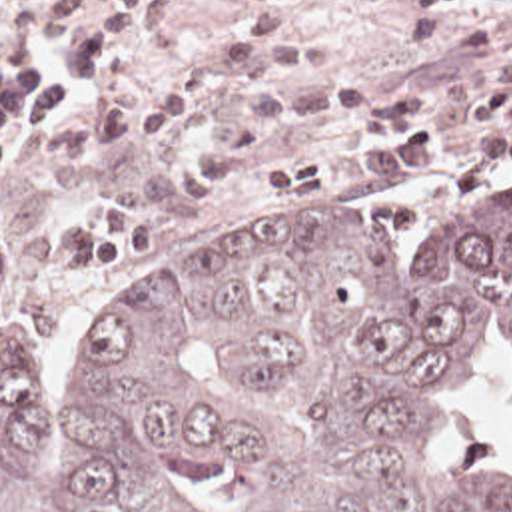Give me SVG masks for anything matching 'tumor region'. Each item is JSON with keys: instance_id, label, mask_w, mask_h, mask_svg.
Wrapping results in <instances>:
<instances>
[{"instance_id": "e687c5a6", "label": "tumor region", "mask_w": 512, "mask_h": 512, "mask_svg": "<svg viewBox=\"0 0 512 512\" xmlns=\"http://www.w3.org/2000/svg\"><path fill=\"white\" fill-rule=\"evenodd\" d=\"M491 310L512 336V206L407 272L343 218L252 228L144 270L54 412L0 284V512H512V474L433 446Z\"/></svg>"}]
</instances>
